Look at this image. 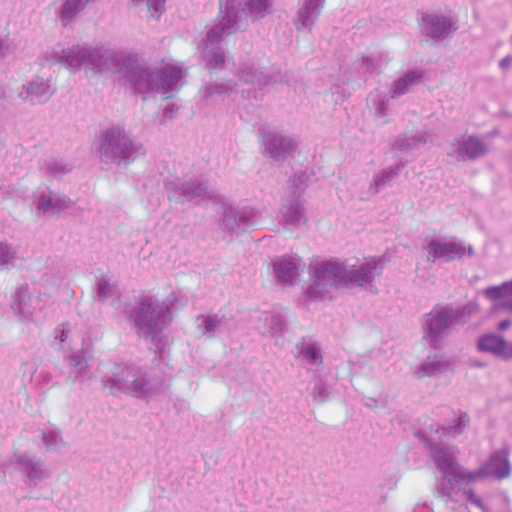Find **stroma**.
I'll return each instance as SVG.
<instances>
[{
	"label": "stroma",
	"mask_w": 512,
	"mask_h": 512,
	"mask_svg": "<svg viewBox=\"0 0 512 512\" xmlns=\"http://www.w3.org/2000/svg\"><path fill=\"white\" fill-rule=\"evenodd\" d=\"M431 220L478 229L512 251V49L465 0H429L423 128L408 208V419L474 407L512 438V364H478L436 382L418 365V322L440 297L419 235Z\"/></svg>",
	"instance_id": "35a3bbf8"
}]
</instances>
